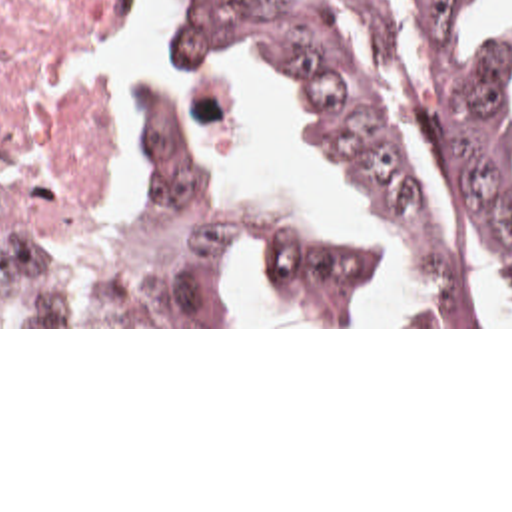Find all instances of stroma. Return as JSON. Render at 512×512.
Segmentation results:
<instances>
[{
    "label": "stroma",
    "mask_w": 512,
    "mask_h": 512,
    "mask_svg": "<svg viewBox=\"0 0 512 512\" xmlns=\"http://www.w3.org/2000/svg\"><path fill=\"white\" fill-rule=\"evenodd\" d=\"M482 0H452V10H454V22L458 26H462L468 34H512V26H490L484 24L476 12L480 8ZM137 4V2H135ZM135 32L133 24L91 46V48L83 49L79 53H75L69 61V71L75 75H83V77H93V79H101L107 83L105 89V99H103V107L107 111V117L111 121V129H113V139H115V169L111 173L109 181H117L119 175V129H117V107H115V73H113V65L107 61H101L99 49L109 48L121 40H125L127 36H131ZM163 53L175 55L177 59H181L183 63H199L203 67H209L213 71L219 73H227L233 77H241V79H249L255 81L263 87H267L279 101L281 105L307 129V133L329 153L333 155L339 165L345 169V173L351 179V211H329L323 203H319L315 197H311L307 191L295 187L293 183H289L283 175H279L277 171L237 153L235 149H231L225 141H221L217 137V119L211 107L201 105L195 101L193 93L171 79L169 73L163 71H137L135 75V151H133V159L129 165V183H139L143 185V99L151 87V83L171 91L175 95V99L181 103V107L187 111V115L191 117V121L197 125V129L215 145L219 147L223 153H227L237 165H241L247 173L267 181V183H275V185H283L289 187L291 191H295L299 197H303L321 217L351 229L355 233L361 235V239L365 241L367 249L373 255L375 261V269H377V295L383 299V303L389 307L393 305L397 299H401L399 293V285H397V277L395 271L391 267L383 237L377 229V225L373 223L359 191L353 179L351 169L345 165V161L337 155L331 139L325 135V131L315 123V119L309 115L305 103L301 101L299 93L295 91L289 75L279 69L275 63H211V61H195L183 53H179L177 48L171 46H161ZM55 161V159H53ZM35 197L39 203H43L45 207L53 209L55 213L75 221V223H97L81 213H77L75 209H71L69 205L53 199V197H45V195H31ZM247 271L251 275L253 281V289H251V297H249V307H247V315H245V323L243 325H0V329H512V325H303V321L299 319L297 311L293 309V305L289 303L287 297H283L279 291H275L257 271H253L247 265Z\"/></svg>",
    "instance_id": "stroma-1"
}]
</instances>
